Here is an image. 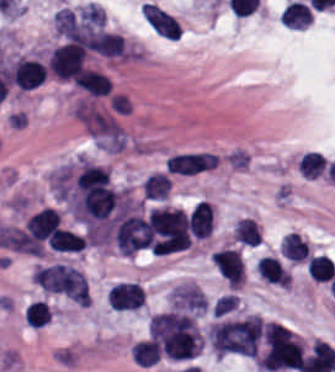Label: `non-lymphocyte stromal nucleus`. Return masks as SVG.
Here are the masks:
<instances>
[{"label": "non-lymphocyte stromal nucleus", "instance_id": "1", "mask_svg": "<svg viewBox=\"0 0 335 372\" xmlns=\"http://www.w3.org/2000/svg\"><path fill=\"white\" fill-rule=\"evenodd\" d=\"M76 114L96 144L104 149H121L125 143V132L119 122L94 105L80 101Z\"/></svg>", "mask_w": 335, "mask_h": 372}, {"label": "non-lymphocyte stromal nucleus", "instance_id": "2", "mask_svg": "<svg viewBox=\"0 0 335 372\" xmlns=\"http://www.w3.org/2000/svg\"><path fill=\"white\" fill-rule=\"evenodd\" d=\"M113 243L124 254H135L150 247L152 235L148 222L132 209H128L110 230Z\"/></svg>", "mask_w": 335, "mask_h": 372}, {"label": "non-lymphocyte stromal nucleus", "instance_id": "3", "mask_svg": "<svg viewBox=\"0 0 335 372\" xmlns=\"http://www.w3.org/2000/svg\"><path fill=\"white\" fill-rule=\"evenodd\" d=\"M140 13L157 35L168 40H178L181 24L174 16L150 3H142Z\"/></svg>", "mask_w": 335, "mask_h": 372}, {"label": "non-lymphocyte stromal nucleus", "instance_id": "4", "mask_svg": "<svg viewBox=\"0 0 335 372\" xmlns=\"http://www.w3.org/2000/svg\"><path fill=\"white\" fill-rule=\"evenodd\" d=\"M218 161V155L208 152L175 153L166 162L168 172L195 174L211 169Z\"/></svg>", "mask_w": 335, "mask_h": 372}, {"label": "non-lymphocyte stromal nucleus", "instance_id": "5", "mask_svg": "<svg viewBox=\"0 0 335 372\" xmlns=\"http://www.w3.org/2000/svg\"><path fill=\"white\" fill-rule=\"evenodd\" d=\"M91 46L104 57L126 58L127 55L125 41L118 32L103 29L93 36Z\"/></svg>", "mask_w": 335, "mask_h": 372}, {"label": "non-lymphocyte stromal nucleus", "instance_id": "6", "mask_svg": "<svg viewBox=\"0 0 335 372\" xmlns=\"http://www.w3.org/2000/svg\"><path fill=\"white\" fill-rule=\"evenodd\" d=\"M171 179L162 172L150 174L142 183V194L146 200H166Z\"/></svg>", "mask_w": 335, "mask_h": 372}, {"label": "non-lymphocyte stromal nucleus", "instance_id": "7", "mask_svg": "<svg viewBox=\"0 0 335 372\" xmlns=\"http://www.w3.org/2000/svg\"><path fill=\"white\" fill-rule=\"evenodd\" d=\"M54 25L56 33L70 40L78 29L73 10L68 7L57 9L54 15Z\"/></svg>", "mask_w": 335, "mask_h": 372}]
</instances>
